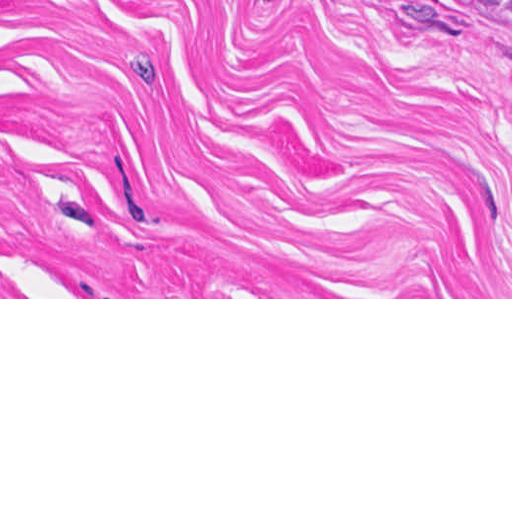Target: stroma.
Here are the masks:
<instances>
[{
  "instance_id": "1",
  "label": "stroma",
  "mask_w": 512,
  "mask_h": 512,
  "mask_svg": "<svg viewBox=\"0 0 512 512\" xmlns=\"http://www.w3.org/2000/svg\"><path fill=\"white\" fill-rule=\"evenodd\" d=\"M0 299H512V34L460 0H0Z\"/></svg>"
}]
</instances>
